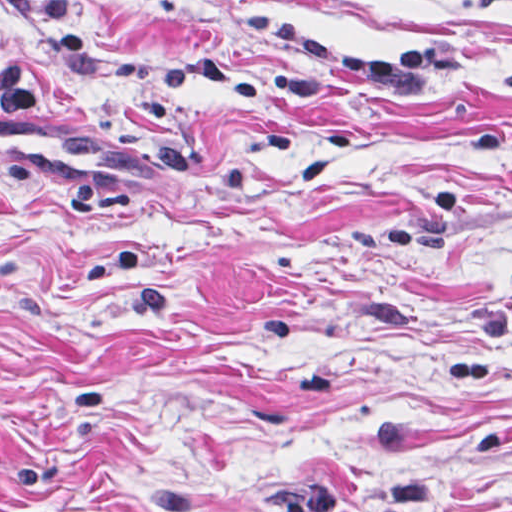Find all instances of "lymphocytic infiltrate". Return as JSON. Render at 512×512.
Instances as JSON below:
<instances>
[{
  "instance_id": "lymphocytic-infiltrate-1",
  "label": "lymphocytic infiltrate",
  "mask_w": 512,
  "mask_h": 512,
  "mask_svg": "<svg viewBox=\"0 0 512 512\" xmlns=\"http://www.w3.org/2000/svg\"><path fill=\"white\" fill-rule=\"evenodd\" d=\"M238 18L317 67L345 73L380 90H419L435 83L448 68L462 67L466 62L454 53L419 52L401 63H377L358 56L340 43L314 39L308 35L301 18L279 17L259 9H245Z\"/></svg>"
}]
</instances>
